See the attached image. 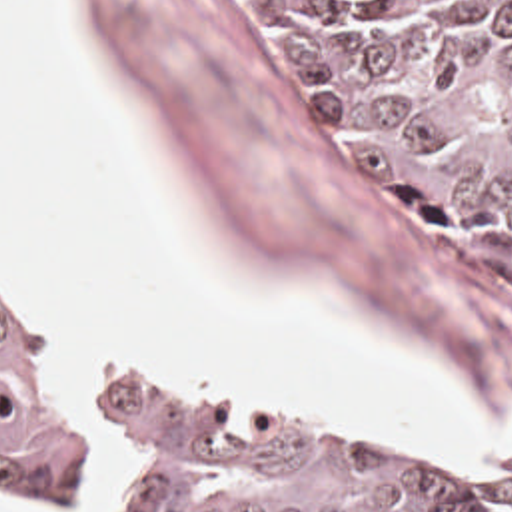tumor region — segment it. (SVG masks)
I'll return each mask as SVG.
<instances>
[{
    "instance_id": "1",
    "label": "tumor region",
    "mask_w": 512,
    "mask_h": 512,
    "mask_svg": "<svg viewBox=\"0 0 512 512\" xmlns=\"http://www.w3.org/2000/svg\"><path fill=\"white\" fill-rule=\"evenodd\" d=\"M244 1L344 175L416 237L512 283V0ZM112 436L134 512H512L466 472L184 377L120 369L76 401L48 315L0 279V482L24 504H94Z\"/></svg>"
}]
</instances>
